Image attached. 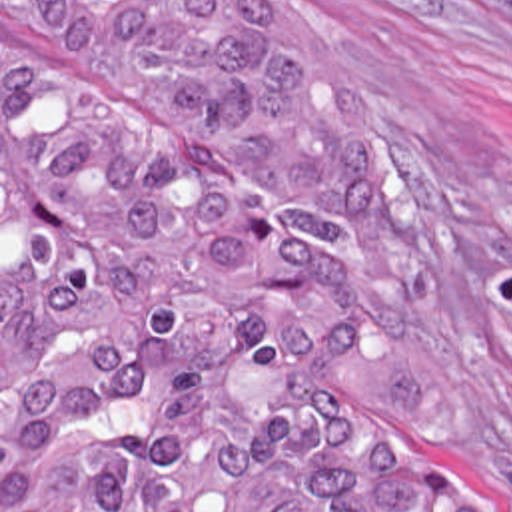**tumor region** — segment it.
<instances>
[{"label":"tumor region","instance_id":"tumor-region-1","mask_svg":"<svg viewBox=\"0 0 512 512\" xmlns=\"http://www.w3.org/2000/svg\"><path fill=\"white\" fill-rule=\"evenodd\" d=\"M337 225L399 227L395 173L280 7L2 0V512H483L357 363L367 283Z\"/></svg>","mask_w":512,"mask_h":512}]
</instances>
